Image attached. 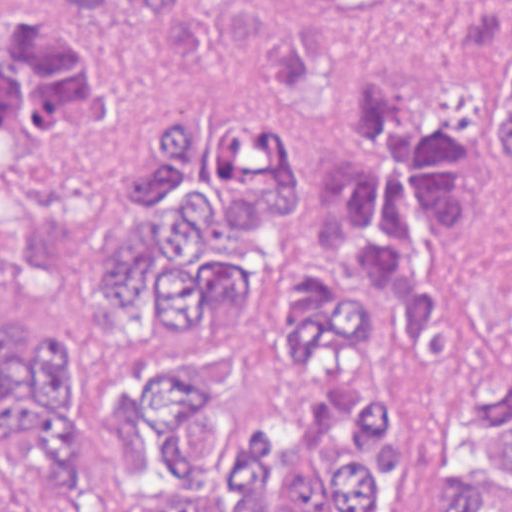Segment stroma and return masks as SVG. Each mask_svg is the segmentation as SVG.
Masks as SVG:
<instances>
[{
  "label": "stroma",
  "mask_w": 512,
  "mask_h": 512,
  "mask_svg": "<svg viewBox=\"0 0 512 512\" xmlns=\"http://www.w3.org/2000/svg\"><path fill=\"white\" fill-rule=\"evenodd\" d=\"M442 0H207L147 17L120 0L101 21L55 0H0V39L49 17L86 36L115 95V117L80 143L19 152L0 179V301L37 310L76 365L84 432L100 470L120 466V401L184 354L174 333L140 346L98 299L95 280L143 237L127 198L160 139L202 116L273 120L290 137L302 199L317 183L333 87L383 77L476 128V233L448 268L453 320L473 361L512 351V176L482 117L478 83L512 43V21L476 35H440ZM412 439L392 512H431L432 469L410 389Z\"/></svg>",
  "instance_id": "35a3bbf8"
}]
</instances>
